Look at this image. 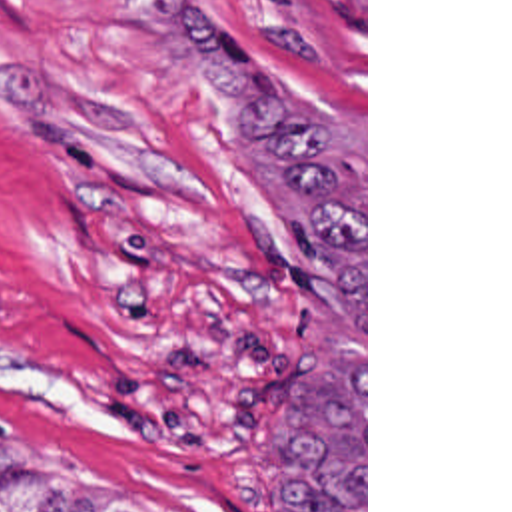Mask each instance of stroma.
<instances>
[{
    "label": "stroma",
    "mask_w": 512,
    "mask_h": 512,
    "mask_svg": "<svg viewBox=\"0 0 512 512\" xmlns=\"http://www.w3.org/2000/svg\"><path fill=\"white\" fill-rule=\"evenodd\" d=\"M364 160V322L162 0H0V461L136 512H292L270 428L298 366L364 368L368 0H200Z\"/></svg>",
    "instance_id": "35a3bbf8"
}]
</instances>
